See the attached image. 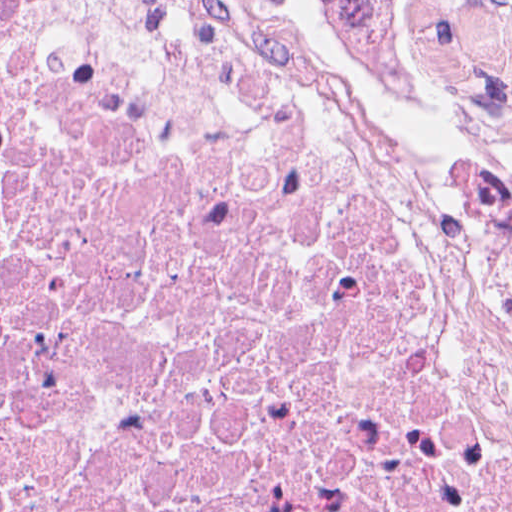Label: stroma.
<instances>
[{
    "instance_id": "1",
    "label": "stroma",
    "mask_w": 512,
    "mask_h": 512,
    "mask_svg": "<svg viewBox=\"0 0 512 512\" xmlns=\"http://www.w3.org/2000/svg\"><path fill=\"white\" fill-rule=\"evenodd\" d=\"M381 43L418 57L447 93L512 116V0H319Z\"/></svg>"
}]
</instances>
